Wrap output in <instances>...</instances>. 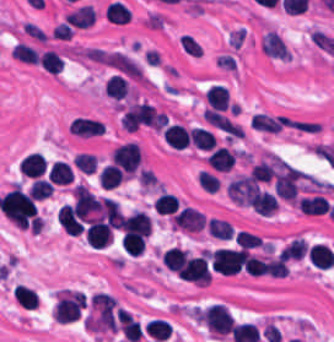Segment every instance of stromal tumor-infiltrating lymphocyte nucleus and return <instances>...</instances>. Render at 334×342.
Masks as SVG:
<instances>
[{"instance_id":"stromal-tumor-infiltrating-lymphocyte-nucleus-28","label":"stromal tumor-infiltrating lymphocyte nucleus","mask_w":334,"mask_h":342,"mask_svg":"<svg viewBox=\"0 0 334 342\" xmlns=\"http://www.w3.org/2000/svg\"><path fill=\"white\" fill-rule=\"evenodd\" d=\"M11 57L18 61L28 64H38V53L27 43L16 42L10 51Z\"/></svg>"},{"instance_id":"stromal-tumor-infiltrating-lymphocyte-nucleus-19","label":"stromal tumor-infiltrating lymphocyte nucleus","mask_w":334,"mask_h":342,"mask_svg":"<svg viewBox=\"0 0 334 342\" xmlns=\"http://www.w3.org/2000/svg\"><path fill=\"white\" fill-rule=\"evenodd\" d=\"M188 140L196 149L209 150L216 145V138L207 128L193 126L188 128Z\"/></svg>"},{"instance_id":"stromal-tumor-infiltrating-lymphocyte-nucleus-14","label":"stromal tumor-infiltrating lymphocyte nucleus","mask_w":334,"mask_h":342,"mask_svg":"<svg viewBox=\"0 0 334 342\" xmlns=\"http://www.w3.org/2000/svg\"><path fill=\"white\" fill-rule=\"evenodd\" d=\"M248 203L250 209L260 216H268L276 210L275 201L271 193L260 190L255 189Z\"/></svg>"},{"instance_id":"stromal-tumor-infiltrating-lymphocyte-nucleus-9","label":"stromal tumor-infiltrating lymphocyte nucleus","mask_w":334,"mask_h":342,"mask_svg":"<svg viewBox=\"0 0 334 342\" xmlns=\"http://www.w3.org/2000/svg\"><path fill=\"white\" fill-rule=\"evenodd\" d=\"M161 135L162 139L173 147L182 149L189 145L187 128L179 122L164 124Z\"/></svg>"},{"instance_id":"stromal-tumor-infiltrating-lymphocyte-nucleus-4","label":"stromal tumor-infiltrating lymphocyte nucleus","mask_w":334,"mask_h":342,"mask_svg":"<svg viewBox=\"0 0 334 342\" xmlns=\"http://www.w3.org/2000/svg\"><path fill=\"white\" fill-rule=\"evenodd\" d=\"M110 163L127 176L134 174L138 167V147L132 142L118 144L110 151Z\"/></svg>"},{"instance_id":"stromal-tumor-infiltrating-lymphocyte-nucleus-22","label":"stromal tumor-infiltrating lymphocyte nucleus","mask_w":334,"mask_h":342,"mask_svg":"<svg viewBox=\"0 0 334 342\" xmlns=\"http://www.w3.org/2000/svg\"><path fill=\"white\" fill-rule=\"evenodd\" d=\"M12 296L22 308L27 310H35L39 300L38 294L33 289L18 283L13 289Z\"/></svg>"},{"instance_id":"stromal-tumor-infiltrating-lymphocyte-nucleus-33","label":"stromal tumor-infiltrating lymphocyte nucleus","mask_w":334,"mask_h":342,"mask_svg":"<svg viewBox=\"0 0 334 342\" xmlns=\"http://www.w3.org/2000/svg\"><path fill=\"white\" fill-rule=\"evenodd\" d=\"M84 240L86 244L93 249H100L107 244L111 237L109 230L84 231Z\"/></svg>"},{"instance_id":"stromal-tumor-infiltrating-lymphocyte-nucleus-8","label":"stromal tumor-infiltrating lymphocyte nucleus","mask_w":334,"mask_h":342,"mask_svg":"<svg viewBox=\"0 0 334 342\" xmlns=\"http://www.w3.org/2000/svg\"><path fill=\"white\" fill-rule=\"evenodd\" d=\"M261 49L270 58L289 59L288 50L277 33L266 30L261 36Z\"/></svg>"},{"instance_id":"stromal-tumor-infiltrating-lymphocyte-nucleus-5","label":"stromal tumor-infiltrating lymphocyte nucleus","mask_w":334,"mask_h":342,"mask_svg":"<svg viewBox=\"0 0 334 342\" xmlns=\"http://www.w3.org/2000/svg\"><path fill=\"white\" fill-rule=\"evenodd\" d=\"M258 187L259 186L252 178L244 175H237L229 182L226 191L228 198L234 204L249 206Z\"/></svg>"},{"instance_id":"stromal-tumor-infiltrating-lymphocyte-nucleus-21","label":"stromal tumor-infiltrating lymphocyte nucleus","mask_w":334,"mask_h":342,"mask_svg":"<svg viewBox=\"0 0 334 342\" xmlns=\"http://www.w3.org/2000/svg\"><path fill=\"white\" fill-rule=\"evenodd\" d=\"M103 92L105 96L118 102L126 98L128 89L125 78L114 74L110 75L105 81Z\"/></svg>"},{"instance_id":"stromal-tumor-infiltrating-lymphocyte-nucleus-34","label":"stromal tumor-infiltrating lymphocyte nucleus","mask_w":334,"mask_h":342,"mask_svg":"<svg viewBox=\"0 0 334 342\" xmlns=\"http://www.w3.org/2000/svg\"><path fill=\"white\" fill-rule=\"evenodd\" d=\"M53 185L50 184L47 180L41 178H34L31 188L29 190V194L33 200H42L48 195H50Z\"/></svg>"},{"instance_id":"stromal-tumor-infiltrating-lymphocyte-nucleus-11","label":"stromal tumor-infiltrating lymphocyte nucleus","mask_w":334,"mask_h":342,"mask_svg":"<svg viewBox=\"0 0 334 342\" xmlns=\"http://www.w3.org/2000/svg\"><path fill=\"white\" fill-rule=\"evenodd\" d=\"M45 168V158L38 151H30L20 162L18 172L29 177H40Z\"/></svg>"},{"instance_id":"stromal-tumor-infiltrating-lymphocyte-nucleus-16","label":"stromal tumor-infiltrating lymphocyte nucleus","mask_w":334,"mask_h":342,"mask_svg":"<svg viewBox=\"0 0 334 342\" xmlns=\"http://www.w3.org/2000/svg\"><path fill=\"white\" fill-rule=\"evenodd\" d=\"M186 253L185 248L172 246L163 250L159 259L163 267L179 276Z\"/></svg>"},{"instance_id":"stromal-tumor-infiltrating-lymphocyte-nucleus-13","label":"stromal tumor-infiltrating lymphocyte nucleus","mask_w":334,"mask_h":342,"mask_svg":"<svg viewBox=\"0 0 334 342\" xmlns=\"http://www.w3.org/2000/svg\"><path fill=\"white\" fill-rule=\"evenodd\" d=\"M207 107L225 110L228 108V89L223 84H210L204 91Z\"/></svg>"},{"instance_id":"stromal-tumor-infiltrating-lymphocyte-nucleus-26","label":"stromal tumor-infiltrating lymphocyte nucleus","mask_w":334,"mask_h":342,"mask_svg":"<svg viewBox=\"0 0 334 342\" xmlns=\"http://www.w3.org/2000/svg\"><path fill=\"white\" fill-rule=\"evenodd\" d=\"M206 228L211 236L220 240H229L233 232L232 224L221 218L211 216L206 220Z\"/></svg>"},{"instance_id":"stromal-tumor-infiltrating-lymphocyte-nucleus-23","label":"stromal tumor-infiltrating lymphocyte nucleus","mask_w":334,"mask_h":342,"mask_svg":"<svg viewBox=\"0 0 334 342\" xmlns=\"http://www.w3.org/2000/svg\"><path fill=\"white\" fill-rule=\"evenodd\" d=\"M99 186L104 189H112L120 185L123 176L119 169L112 164H105L100 167L97 175Z\"/></svg>"},{"instance_id":"stromal-tumor-infiltrating-lymphocyte-nucleus-7","label":"stromal tumor-infiltrating lymphocyte nucleus","mask_w":334,"mask_h":342,"mask_svg":"<svg viewBox=\"0 0 334 342\" xmlns=\"http://www.w3.org/2000/svg\"><path fill=\"white\" fill-rule=\"evenodd\" d=\"M119 229L121 233L148 236L151 227L146 214L142 210H134L121 216Z\"/></svg>"},{"instance_id":"stromal-tumor-infiltrating-lymphocyte-nucleus-3","label":"stromal tumor-infiltrating lymphocyte nucleus","mask_w":334,"mask_h":342,"mask_svg":"<svg viewBox=\"0 0 334 342\" xmlns=\"http://www.w3.org/2000/svg\"><path fill=\"white\" fill-rule=\"evenodd\" d=\"M178 278L208 284L211 280L208 250L186 255Z\"/></svg>"},{"instance_id":"stromal-tumor-infiltrating-lymphocyte-nucleus-32","label":"stromal tumor-infiltrating lymphocyte nucleus","mask_w":334,"mask_h":342,"mask_svg":"<svg viewBox=\"0 0 334 342\" xmlns=\"http://www.w3.org/2000/svg\"><path fill=\"white\" fill-rule=\"evenodd\" d=\"M97 158L94 154L77 152L71 158L72 166L83 173H92L95 169Z\"/></svg>"},{"instance_id":"stromal-tumor-infiltrating-lymphocyte-nucleus-2","label":"stromal tumor-infiltrating lymphocyte nucleus","mask_w":334,"mask_h":342,"mask_svg":"<svg viewBox=\"0 0 334 342\" xmlns=\"http://www.w3.org/2000/svg\"><path fill=\"white\" fill-rule=\"evenodd\" d=\"M201 322L210 333L223 337L229 333L233 317L225 305L211 302L202 309Z\"/></svg>"},{"instance_id":"stromal-tumor-infiltrating-lymphocyte-nucleus-12","label":"stromal tumor-infiltrating lymphocyte nucleus","mask_w":334,"mask_h":342,"mask_svg":"<svg viewBox=\"0 0 334 342\" xmlns=\"http://www.w3.org/2000/svg\"><path fill=\"white\" fill-rule=\"evenodd\" d=\"M299 213L304 215H322L329 208L327 199L320 194L304 196L297 201Z\"/></svg>"},{"instance_id":"stromal-tumor-infiltrating-lymphocyte-nucleus-20","label":"stromal tumor-infiltrating lymphocyte nucleus","mask_w":334,"mask_h":342,"mask_svg":"<svg viewBox=\"0 0 334 342\" xmlns=\"http://www.w3.org/2000/svg\"><path fill=\"white\" fill-rule=\"evenodd\" d=\"M118 320L121 335L129 342H138L141 336L139 322L126 312H119Z\"/></svg>"},{"instance_id":"stromal-tumor-infiltrating-lymphocyte-nucleus-30","label":"stromal tumor-infiltrating lymphocyte nucleus","mask_w":334,"mask_h":342,"mask_svg":"<svg viewBox=\"0 0 334 342\" xmlns=\"http://www.w3.org/2000/svg\"><path fill=\"white\" fill-rule=\"evenodd\" d=\"M129 15L130 13L125 5L114 0L107 4L104 11L105 20L114 23H124L127 21Z\"/></svg>"},{"instance_id":"stromal-tumor-infiltrating-lymphocyte-nucleus-10","label":"stromal tumor-infiltrating lymphocyte nucleus","mask_w":334,"mask_h":342,"mask_svg":"<svg viewBox=\"0 0 334 342\" xmlns=\"http://www.w3.org/2000/svg\"><path fill=\"white\" fill-rule=\"evenodd\" d=\"M235 154L224 145H217L207 156V165L216 172H227L233 165Z\"/></svg>"},{"instance_id":"stromal-tumor-infiltrating-lymphocyte-nucleus-1","label":"stromal tumor-infiltrating lymphocyte nucleus","mask_w":334,"mask_h":342,"mask_svg":"<svg viewBox=\"0 0 334 342\" xmlns=\"http://www.w3.org/2000/svg\"><path fill=\"white\" fill-rule=\"evenodd\" d=\"M85 305L83 291L57 290L51 314L56 322H70L79 317Z\"/></svg>"},{"instance_id":"stromal-tumor-infiltrating-lymphocyte-nucleus-24","label":"stromal tumor-infiltrating lymphocyte nucleus","mask_w":334,"mask_h":342,"mask_svg":"<svg viewBox=\"0 0 334 342\" xmlns=\"http://www.w3.org/2000/svg\"><path fill=\"white\" fill-rule=\"evenodd\" d=\"M143 329L148 338L159 342H164L170 333V325L163 318H150Z\"/></svg>"},{"instance_id":"stromal-tumor-infiltrating-lymphocyte-nucleus-6","label":"stromal tumor-infiltrating lymphocyte nucleus","mask_w":334,"mask_h":342,"mask_svg":"<svg viewBox=\"0 0 334 342\" xmlns=\"http://www.w3.org/2000/svg\"><path fill=\"white\" fill-rule=\"evenodd\" d=\"M205 221L204 214L184 205L173 215L170 221V229L196 232L202 229Z\"/></svg>"},{"instance_id":"stromal-tumor-infiltrating-lymphocyte-nucleus-29","label":"stromal tumor-infiltrating lymphocyte nucleus","mask_w":334,"mask_h":342,"mask_svg":"<svg viewBox=\"0 0 334 342\" xmlns=\"http://www.w3.org/2000/svg\"><path fill=\"white\" fill-rule=\"evenodd\" d=\"M152 208L156 214L171 215L178 208V203L173 194L159 193L152 203Z\"/></svg>"},{"instance_id":"stromal-tumor-infiltrating-lymphocyte-nucleus-17","label":"stromal tumor-infiltrating lymphocyte nucleus","mask_w":334,"mask_h":342,"mask_svg":"<svg viewBox=\"0 0 334 342\" xmlns=\"http://www.w3.org/2000/svg\"><path fill=\"white\" fill-rule=\"evenodd\" d=\"M93 20V9L88 4H81L62 19L64 25L77 28H84Z\"/></svg>"},{"instance_id":"stromal-tumor-infiltrating-lymphocyte-nucleus-15","label":"stromal tumor-infiltrating lymphocyte nucleus","mask_w":334,"mask_h":342,"mask_svg":"<svg viewBox=\"0 0 334 342\" xmlns=\"http://www.w3.org/2000/svg\"><path fill=\"white\" fill-rule=\"evenodd\" d=\"M146 236L135 231H124L119 240L122 251L129 257H137L142 253Z\"/></svg>"},{"instance_id":"stromal-tumor-infiltrating-lymphocyte-nucleus-25","label":"stromal tumor-infiltrating lymphocyte nucleus","mask_w":334,"mask_h":342,"mask_svg":"<svg viewBox=\"0 0 334 342\" xmlns=\"http://www.w3.org/2000/svg\"><path fill=\"white\" fill-rule=\"evenodd\" d=\"M73 173L67 162L55 160L49 167L48 179L55 184L71 182Z\"/></svg>"},{"instance_id":"stromal-tumor-infiltrating-lymphocyte-nucleus-18","label":"stromal tumor-infiltrating lymphocyte nucleus","mask_w":334,"mask_h":342,"mask_svg":"<svg viewBox=\"0 0 334 342\" xmlns=\"http://www.w3.org/2000/svg\"><path fill=\"white\" fill-rule=\"evenodd\" d=\"M333 255L330 247L315 242L308 252L307 259L315 268L327 269L332 263Z\"/></svg>"},{"instance_id":"stromal-tumor-infiltrating-lymphocyte-nucleus-27","label":"stromal tumor-infiltrating lymphocyte nucleus","mask_w":334,"mask_h":342,"mask_svg":"<svg viewBox=\"0 0 334 342\" xmlns=\"http://www.w3.org/2000/svg\"><path fill=\"white\" fill-rule=\"evenodd\" d=\"M62 62L63 61L60 58L59 54L52 48H45L44 50L39 52V66L47 72H50L55 75L56 72L59 70Z\"/></svg>"},{"instance_id":"stromal-tumor-infiltrating-lymphocyte-nucleus-31","label":"stromal tumor-infiltrating lymphocyte nucleus","mask_w":334,"mask_h":342,"mask_svg":"<svg viewBox=\"0 0 334 342\" xmlns=\"http://www.w3.org/2000/svg\"><path fill=\"white\" fill-rule=\"evenodd\" d=\"M273 172L272 161L260 160L251 166L248 175L255 181L268 182Z\"/></svg>"}]
</instances>
